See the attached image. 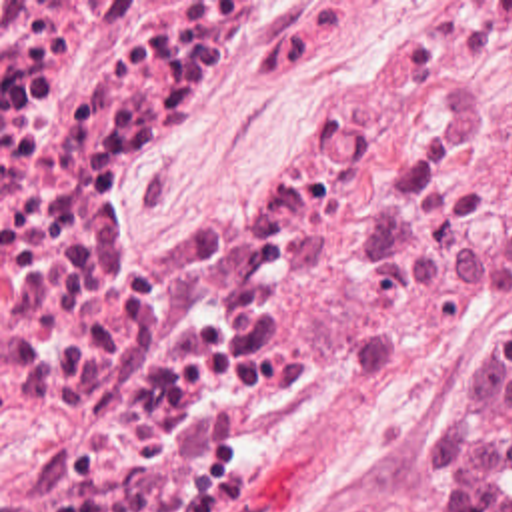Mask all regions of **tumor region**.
Returning a JSON list of instances; mask_svg holds the SVG:
<instances>
[{
  "label": "tumor region",
  "mask_w": 512,
  "mask_h": 512,
  "mask_svg": "<svg viewBox=\"0 0 512 512\" xmlns=\"http://www.w3.org/2000/svg\"><path fill=\"white\" fill-rule=\"evenodd\" d=\"M452 512H512V332L498 334L430 460Z\"/></svg>",
  "instance_id": "obj_1"
}]
</instances>
